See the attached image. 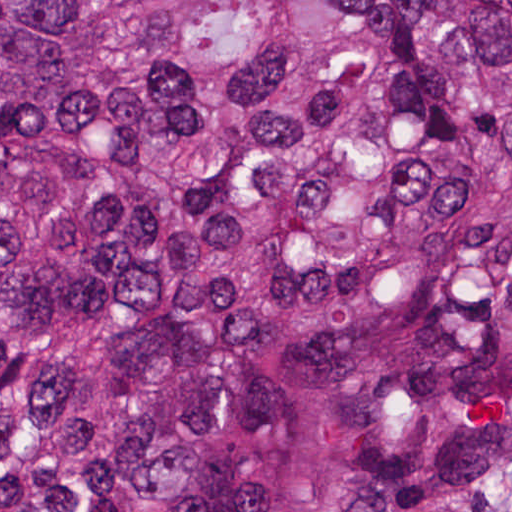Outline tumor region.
<instances>
[{
    "label": "tumor region",
    "instance_id": "1",
    "mask_svg": "<svg viewBox=\"0 0 512 512\" xmlns=\"http://www.w3.org/2000/svg\"><path fill=\"white\" fill-rule=\"evenodd\" d=\"M0 512H512V0H0Z\"/></svg>",
    "mask_w": 512,
    "mask_h": 512
}]
</instances>
